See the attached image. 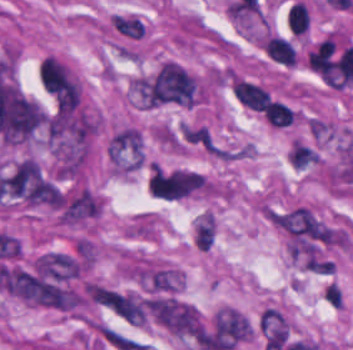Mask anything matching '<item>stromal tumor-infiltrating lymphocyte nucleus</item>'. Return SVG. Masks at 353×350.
I'll list each match as a JSON object with an SVG mask.
<instances>
[{
    "label": "stromal tumor-infiltrating lymphocyte nucleus",
    "instance_id": "3",
    "mask_svg": "<svg viewBox=\"0 0 353 350\" xmlns=\"http://www.w3.org/2000/svg\"><path fill=\"white\" fill-rule=\"evenodd\" d=\"M261 113L275 127H286L293 119L291 108L277 100H270Z\"/></svg>",
    "mask_w": 353,
    "mask_h": 350
},
{
    "label": "stromal tumor-infiltrating lymphocyte nucleus",
    "instance_id": "1",
    "mask_svg": "<svg viewBox=\"0 0 353 350\" xmlns=\"http://www.w3.org/2000/svg\"><path fill=\"white\" fill-rule=\"evenodd\" d=\"M234 94L242 104L260 112L270 98V95L260 86L238 79L234 84Z\"/></svg>",
    "mask_w": 353,
    "mask_h": 350
},
{
    "label": "stromal tumor-infiltrating lymphocyte nucleus",
    "instance_id": "2",
    "mask_svg": "<svg viewBox=\"0 0 353 350\" xmlns=\"http://www.w3.org/2000/svg\"><path fill=\"white\" fill-rule=\"evenodd\" d=\"M267 57L281 64L293 66L296 61V53L286 39L269 36L262 43Z\"/></svg>",
    "mask_w": 353,
    "mask_h": 350
},
{
    "label": "stromal tumor-infiltrating lymphocyte nucleus",
    "instance_id": "4",
    "mask_svg": "<svg viewBox=\"0 0 353 350\" xmlns=\"http://www.w3.org/2000/svg\"><path fill=\"white\" fill-rule=\"evenodd\" d=\"M287 21L291 32L304 33L309 27V9L306 4L294 2L288 9Z\"/></svg>",
    "mask_w": 353,
    "mask_h": 350
}]
</instances>
